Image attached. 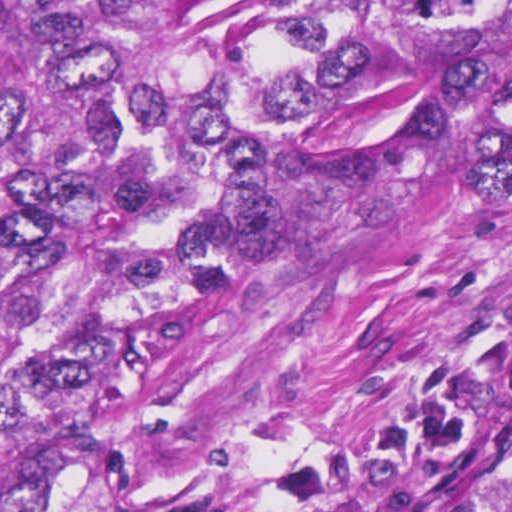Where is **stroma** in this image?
<instances>
[{
  "mask_svg": "<svg viewBox=\"0 0 512 512\" xmlns=\"http://www.w3.org/2000/svg\"><path fill=\"white\" fill-rule=\"evenodd\" d=\"M94 462L127 512H413L512 465V128L350 178Z\"/></svg>",
  "mask_w": 512,
  "mask_h": 512,
  "instance_id": "35a3bbf8",
  "label": "stroma"
}]
</instances>
